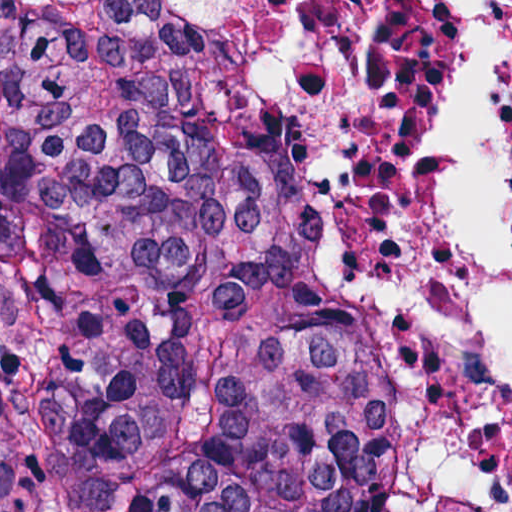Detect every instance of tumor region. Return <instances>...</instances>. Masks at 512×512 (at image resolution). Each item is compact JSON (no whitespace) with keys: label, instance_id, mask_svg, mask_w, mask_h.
<instances>
[{"label":"tumor region","instance_id":"e687c5a6","mask_svg":"<svg viewBox=\"0 0 512 512\" xmlns=\"http://www.w3.org/2000/svg\"><path fill=\"white\" fill-rule=\"evenodd\" d=\"M353 140L244 27L0 1V512H435Z\"/></svg>","mask_w":512,"mask_h":512}]
</instances>
